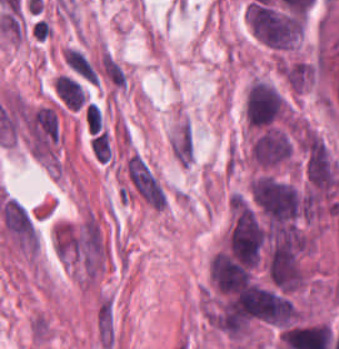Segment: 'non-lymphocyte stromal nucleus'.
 Returning <instances> with one entry per match:
<instances>
[{
	"instance_id": "dd21d789",
	"label": "non-lymphocyte stromal nucleus",
	"mask_w": 339,
	"mask_h": 349,
	"mask_svg": "<svg viewBox=\"0 0 339 349\" xmlns=\"http://www.w3.org/2000/svg\"><path fill=\"white\" fill-rule=\"evenodd\" d=\"M22 130L33 156H51L59 140V115L54 106L40 104L22 110Z\"/></svg>"
},
{
	"instance_id": "a72fc3eb",
	"label": "non-lymphocyte stromal nucleus",
	"mask_w": 339,
	"mask_h": 349,
	"mask_svg": "<svg viewBox=\"0 0 339 349\" xmlns=\"http://www.w3.org/2000/svg\"><path fill=\"white\" fill-rule=\"evenodd\" d=\"M0 224L14 245L34 253L36 228L32 215L22 204L11 197H4L0 203Z\"/></svg>"
},
{
	"instance_id": "3746e769",
	"label": "non-lymphocyte stromal nucleus",
	"mask_w": 339,
	"mask_h": 349,
	"mask_svg": "<svg viewBox=\"0 0 339 349\" xmlns=\"http://www.w3.org/2000/svg\"><path fill=\"white\" fill-rule=\"evenodd\" d=\"M130 181L150 205L164 208V192L143 159L135 153L125 162Z\"/></svg>"
},
{
	"instance_id": "fc2b8d12",
	"label": "non-lymphocyte stromal nucleus",
	"mask_w": 339,
	"mask_h": 349,
	"mask_svg": "<svg viewBox=\"0 0 339 349\" xmlns=\"http://www.w3.org/2000/svg\"><path fill=\"white\" fill-rule=\"evenodd\" d=\"M170 147L175 159L180 162L189 163L193 156V143L190 129L183 121L174 132Z\"/></svg>"
}]
</instances>
